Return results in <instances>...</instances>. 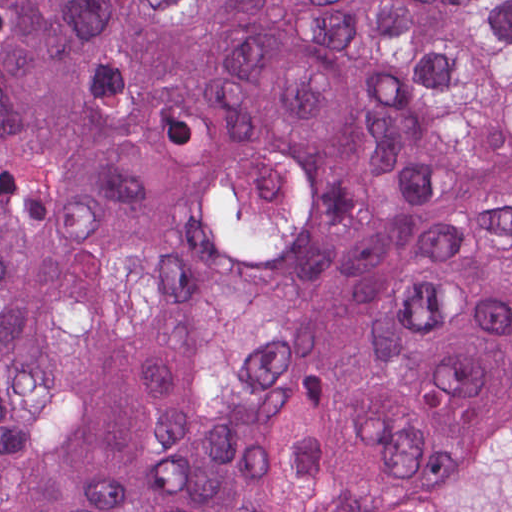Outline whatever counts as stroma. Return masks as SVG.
I'll return each instance as SVG.
<instances>
[{
    "mask_svg": "<svg viewBox=\"0 0 512 512\" xmlns=\"http://www.w3.org/2000/svg\"><path fill=\"white\" fill-rule=\"evenodd\" d=\"M265 147L303 163L304 227L289 247L274 255L236 256L225 251L206 205L197 218L199 204L220 168ZM190 248L209 283L244 292H267L311 260L360 379L382 409L418 418L471 412L474 429L464 442L334 512H512V402L434 404L379 377L355 339V304L345 276L333 178L318 148L288 132H263L233 147L178 220L91 259L61 279L18 320L0 328V351L37 343L139 278L178 261Z\"/></svg>",
    "mask_w": 512,
    "mask_h": 512,
    "instance_id": "obj_1",
    "label": "stroma"
}]
</instances>
